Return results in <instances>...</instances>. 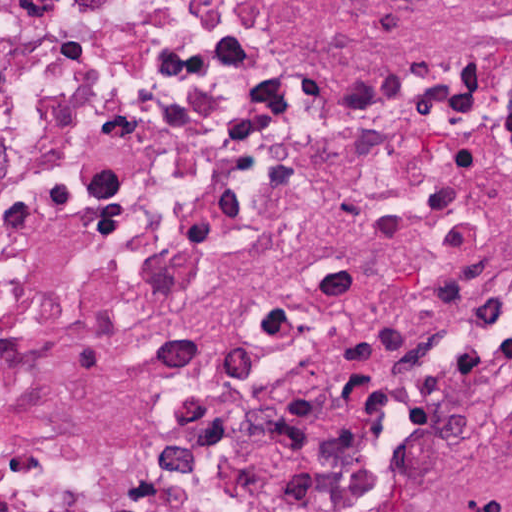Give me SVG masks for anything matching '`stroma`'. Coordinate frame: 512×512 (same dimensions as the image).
I'll list each match as a JSON object with an SVG mask.
<instances>
[{
    "instance_id": "1",
    "label": "stroma",
    "mask_w": 512,
    "mask_h": 512,
    "mask_svg": "<svg viewBox=\"0 0 512 512\" xmlns=\"http://www.w3.org/2000/svg\"><path fill=\"white\" fill-rule=\"evenodd\" d=\"M386 512H512V343L463 365L429 397Z\"/></svg>"
}]
</instances>
